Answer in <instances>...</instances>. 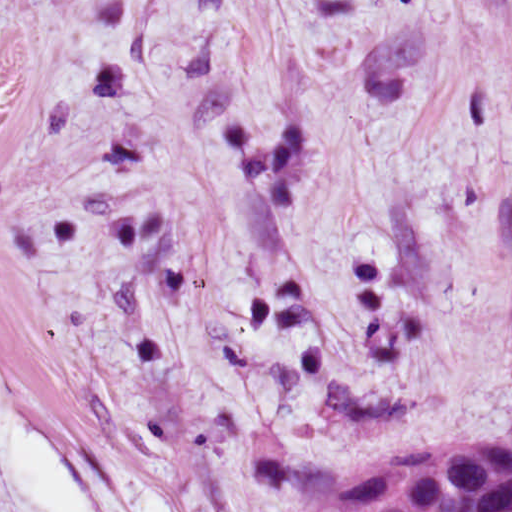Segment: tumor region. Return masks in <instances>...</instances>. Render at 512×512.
Here are the masks:
<instances>
[{
    "label": "tumor region",
    "mask_w": 512,
    "mask_h": 512,
    "mask_svg": "<svg viewBox=\"0 0 512 512\" xmlns=\"http://www.w3.org/2000/svg\"><path fill=\"white\" fill-rule=\"evenodd\" d=\"M507 10L512 23V0ZM283 512H512V438L377 454Z\"/></svg>",
    "instance_id": "tumor-region-1"
}]
</instances>
